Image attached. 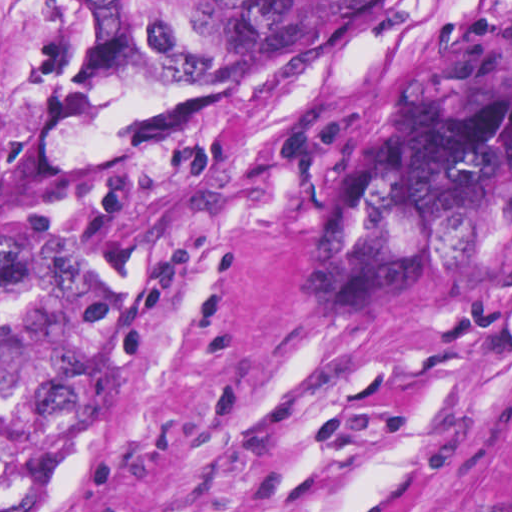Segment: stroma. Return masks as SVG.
Masks as SVG:
<instances>
[{
  "label": "stroma",
  "mask_w": 512,
  "mask_h": 512,
  "mask_svg": "<svg viewBox=\"0 0 512 512\" xmlns=\"http://www.w3.org/2000/svg\"><path fill=\"white\" fill-rule=\"evenodd\" d=\"M265 91L152 283L100 512H512V0H392ZM229 92L114 85L0 0V244L48 158Z\"/></svg>",
  "instance_id": "1"
}]
</instances>
